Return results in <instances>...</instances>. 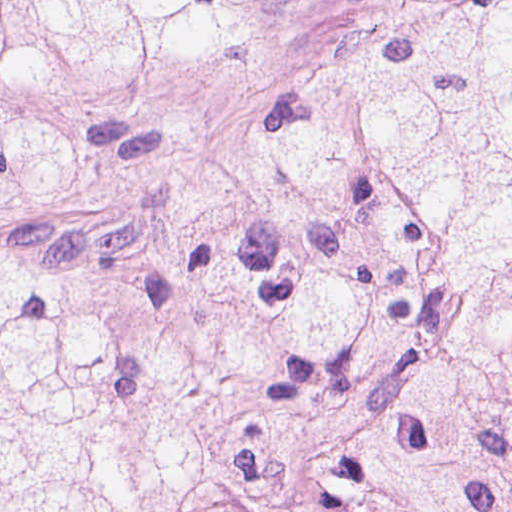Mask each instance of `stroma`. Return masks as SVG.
I'll return each mask as SVG.
<instances>
[{
    "label": "stroma",
    "mask_w": 512,
    "mask_h": 512,
    "mask_svg": "<svg viewBox=\"0 0 512 512\" xmlns=\"http://www.w3.org/2000/svg\"><path fill=\"white\" fill-rule=\"evenodd\" d=\"M403 0H281L199 62L74 92L0 57V124L59 131L49 201L0 205V243L107 293L158 291L222 134Z\"/></svg>",
    "instance_id": "35a3bbf8"
}]
</instances>
